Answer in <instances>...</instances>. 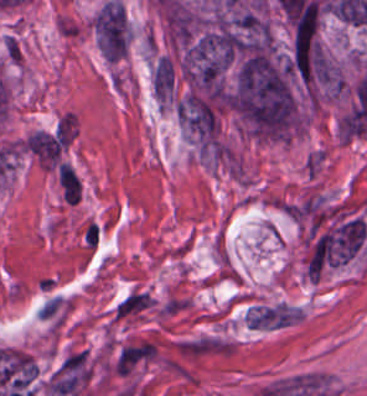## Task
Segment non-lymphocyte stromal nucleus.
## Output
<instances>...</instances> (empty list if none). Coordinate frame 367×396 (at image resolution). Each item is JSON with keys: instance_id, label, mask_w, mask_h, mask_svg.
I'll list each match as a JSON object with an SVG mask.
<instances>
[{"instance_id": "obj_1", "label": "non-lymphocyte stromal nucleus", "mask_w": 367, "mask_h": 396, "mask_svg": "<svg viewBox=\"0 0 367 396\" xmlns=\"http://www.w3.org/2000/svg\"><path fill=\"white\" fill-rule=\"evenodd\" d=\"M175 347L179 353L188 357L222 355L234 351L232 340L211 334L175 340Z\"/></svg>"}, {"instance_id": "obj_2", "label": "non-lymphocyte stromal nucleus", "mask_w": 367, "mask_h": 396, "mask_svg": "<svg viewBox=\"0 0 367 396\" xmlns=\"http://www.w3.org/2000/svg\"><path fill=\"white\" fill-rule=\"evenodd\" d=\"M59 181L65 202L75 204L79 198V182L72 166L59 164Z\"/></svg>"}]
</instances>
